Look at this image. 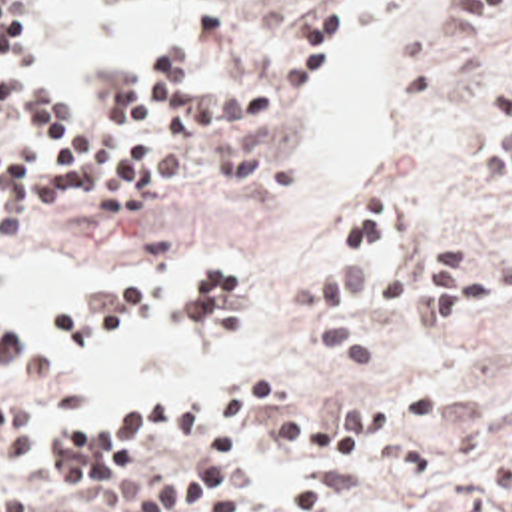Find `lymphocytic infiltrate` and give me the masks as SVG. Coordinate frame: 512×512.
Instances as JSON below:
<instances>
[{"label":"lymphocytic infiltrate","mask_w":512,"mask_h":512,"mask_svg":"<svg viewBox=\"0 0 512 512\" xmlns=\"http://www.w3.org/2000/svg\"><path fill=\"white\" fill-rule=\"evenodd\" d=\"M57 0H0V244L21 242L59 206L107 232H129L161 186L201 154H241L265 141L313 87L331 55V7L317 3L285 23L253 61L215 87H187L191 65L225 41L219 3L163 53L143 59L117 103H65L21 65ZM463 45L491 47L512 31V0H455ZM497 119L481 141L479 172L512 192V47L493 81ZM407 200L387 178L357 184L329 220L319 270L287 280L281 308L311 322L313 346L335 372L375 366V340L351 316L359 298L417 320L433 336L512 302V256L479 262L465 242L421 246L387 282L375 262L405 224ZM183 288L117 286L89 300L83 332L101 340L129 324H167L201 346L239 314V276L223 260H193ZM457 316V318H455ZM455 318L451 324H439ZM41 360L29 334L0 314V386H31ZM191 400L137 402L59 426L61 474L81 498L113 512H231L243 450L257 426L265 448L295 450L351 470H381L411 486L441 480L435 452L415 430L441 418V388L409 384L395 396L265 414V382L247 386L209 436L201 460L165 464L135 456V444L189 426ZM43 400H0V512H33L9 474L41 446ZM97 506V504H95Z\"/></svg>","instance_id":"obj_1"}]
</instances>
